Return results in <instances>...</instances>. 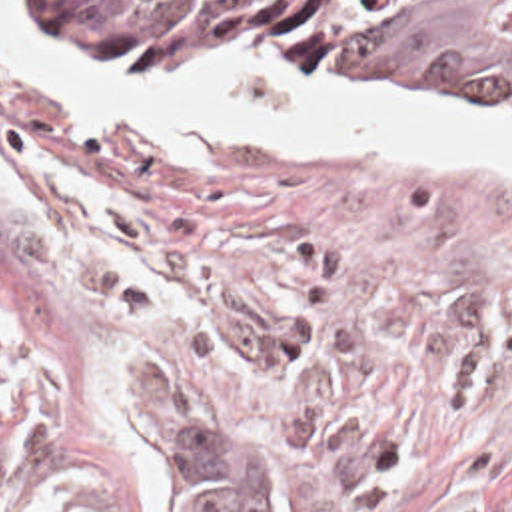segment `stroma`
I'll list each match as a JSON object with an SVG mask.
<instances>
[{"label":"stroma","mask_w":512,"mask_h":512,"mask_svg":"<svg viewBox=\"0 0 512 512\" xmlns=\"http://www.w3.org/2000/svg\"><path fill=\"white\" fill-rule=\"evenodd\" d=\"M125 79L308 81L512 137V113L418 103L322 55ZM0 309V512H163L145 393L205 411L187 415L269 475L273 512H512V173L486 161L171 143L0 45Z\"/></svg>","instance_id":"1"}]
</instances>
